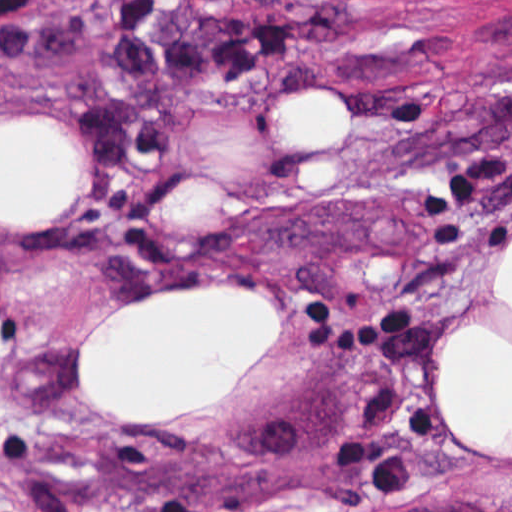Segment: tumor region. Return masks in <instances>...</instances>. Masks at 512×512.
Segmentation results:
<instances>
[{"label":"tumor region","mask_w":512,"mask_h":512,"mask_svg":"<svg viewBox=\"0 0 512 512\" xmlns=\"http://www.w3.org/2000/svg\"><path fill=\"white\" fill-rule=\"evenodd\" d=\"M16 0H0V22ZM269 0H117L108 68L119 103L77 115L96 175L117 187L129 161L159 153L168 140L164 103L203 76L248 78L271 60L344 29V11L319 5L263 17Z\"/></svg>","instance_id":"e687c5a6"}]
</instances>
